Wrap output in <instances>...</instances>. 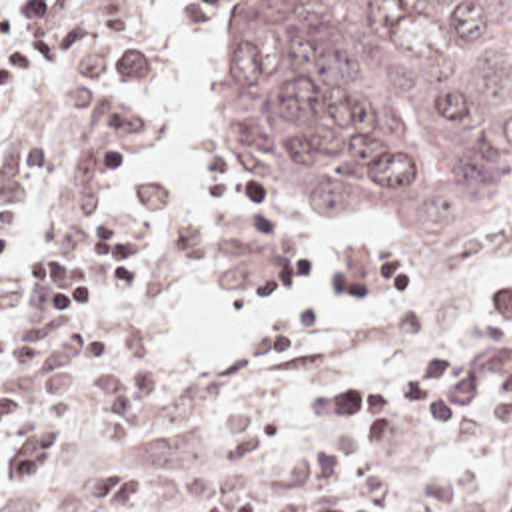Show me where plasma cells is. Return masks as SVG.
<instances>
[{
    "label": "plasma cells",
    "mask_w": 512,
    "mask_h": 512,
    "mask_svg": "<svg viewBox=\"0 0 512 512\" xmlns=\"http://www.w3.org/2000/svg\"><path fill=\"white\" fill-rule=\"evenodd\" d=\"M483 335L461 345L421 351L411 373L383 385H363L357 371L309 377L299 409L277 423L258 403L232 401L220 415V443L230 467L258 471L301 445L283 461L277 477L283 493L218 491L200 512H457L463 487L457 477L429 475L415 483L393 511H365L341 491L339 463L319 447L313 419L345 421V445L353 453L389 447L421 421L461 425L481 409L491 429L512 427V284L483 321Z\"/></svg>",
    "instance_id": "plasma-cells-1"
}]
</instances>
